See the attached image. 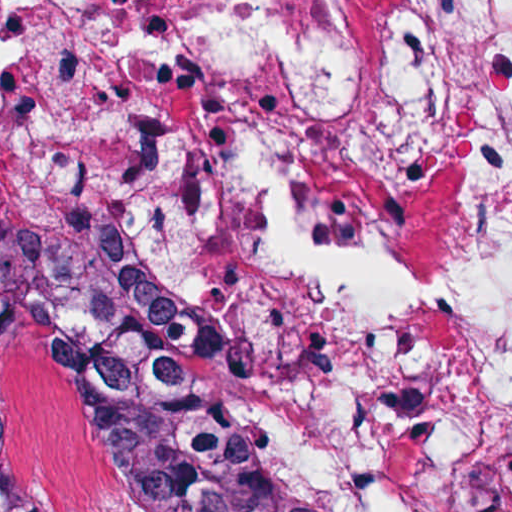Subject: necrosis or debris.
<instances>
[{
  "label": "necrosis or debris",
  "instance_id": "1",
  "mask_svg": "<svg viewBox=\"0 0 512 512\" xmlns=\"http://www.w3.org/2000/svg\"><path fill=\"white\" fill-rule=\"evenodd\" d=\"M0 270L341 511L512 512V0H0Z\"/></svg>",
  "mask_w": 512,
  "mask_h": 512
}]
</instances>
